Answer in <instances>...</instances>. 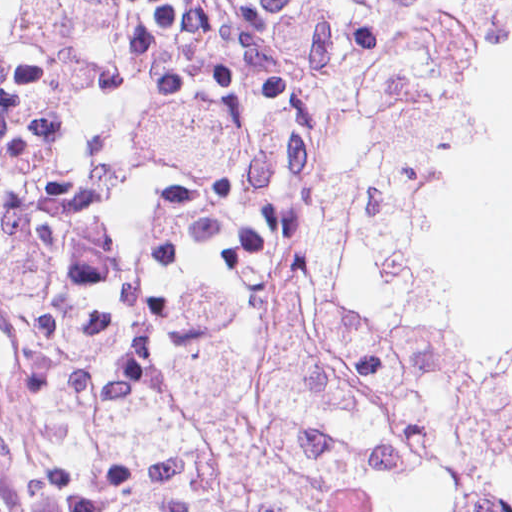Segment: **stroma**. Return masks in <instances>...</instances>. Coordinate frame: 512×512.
Instances as JSON below:
<instances>
[{"mask_svg": "<svg viewBox=\"0 0 512 512\" xmlns=\"http://www.w3.org/2000/svg\"><path fill=\"white\" fill-rule=\"evenodd\" d=\"M511 2L412 0L403 14L400 22L423 12L465 18L484 33L488 51L478 100L399 217L427 201L499 92L490 29L496 13ZM415 313L464 334L439 317ZM83 367L48 364L0 274V512H131L118 500L101 436L77 397ZM356 499L326 509H347Z\"/></svg>", "mask_w": 512, "mask_h": 512, "instance_id": "35a3bbf8", "label": "stroma"}]
</instances>
